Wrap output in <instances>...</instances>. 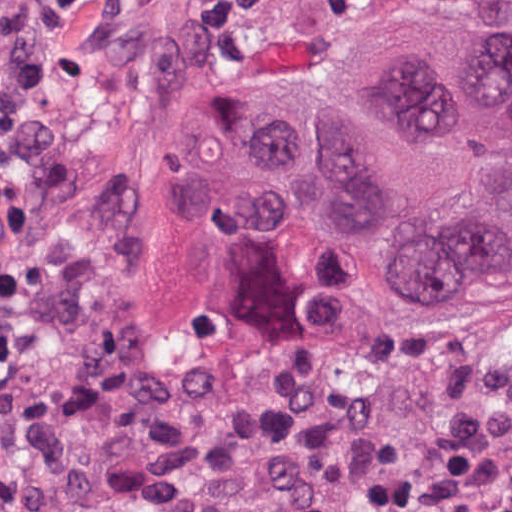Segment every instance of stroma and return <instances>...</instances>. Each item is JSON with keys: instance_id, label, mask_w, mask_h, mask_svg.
<instances>
[{"instance_id": "stroma-1", "label": "stroma", "mask_w": 512, "mask_h": 512, "mask_svg": "<svg viewBox=\"0 0 512 512\" xmlns=\"http://www.w3.org/2000/svg\"><path fill=\"white\" fill-rule=\"evenodd\" d=\"M411 22L492 37L512 0H93L62 41L50 136L12 161L24 226L0 283L36 314L0 466V512H251L186 469L204 419L290 371L328 373L375 426L331 458L329 493L453 461L483 512H512V300L404 327L364 248L305 212L246 230L166 205L157 165L209 92L283 66L315 82Z\"/></svg>"}]
</instances>
